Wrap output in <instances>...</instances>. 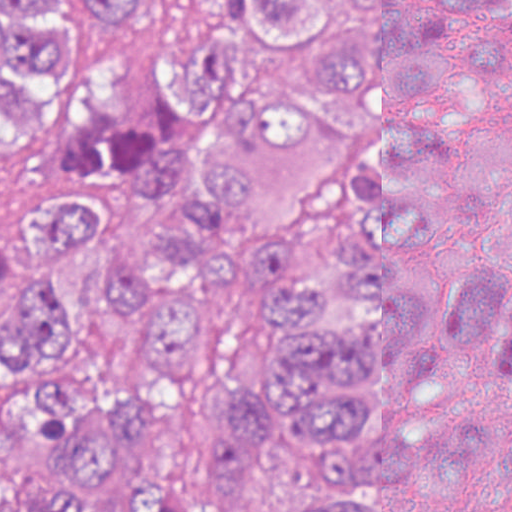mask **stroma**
I'll list each match as a JSON object with an SVG mask.
<instances>
[{
	"instance_id": "stroma-1",
	"label": "stroma",
	"mask_w": 512,
	"mask_h": 512,
	"mask_svg": "<svg viewBox=\"0 0 512 512\" xmlns=\"http://www.w3.org/2000/svg\"><path fill=\"white\" fill-rule=\"evenodd\" d=\"M131 51L124 43L82 84L66 111L33 135H0V224L15 214L38 178L52 147L75 126L120 107L130 90ZM326 166H308L233 217L282 244L300 240L319 203ZM72 281L80 298L77 341L49 375H8L0 366V403L61 375L87 371L107 380L132 405L184 410L164 419L155 433L132 444L121 484L96 512H130L148 473L189 485L187 512H212L227 497L200 469L220 428L212 411L228 374L272 368L275 331L263 316L252 276L236 261L205 287L194 326L190 371L174 386L154 383L122 307L102 299L91 284V261L72 257ZM449 420L512 425L488 411ZM365 512H406L396 486L361 484L344 491Z\"/></svg>"
}]
</instances>
